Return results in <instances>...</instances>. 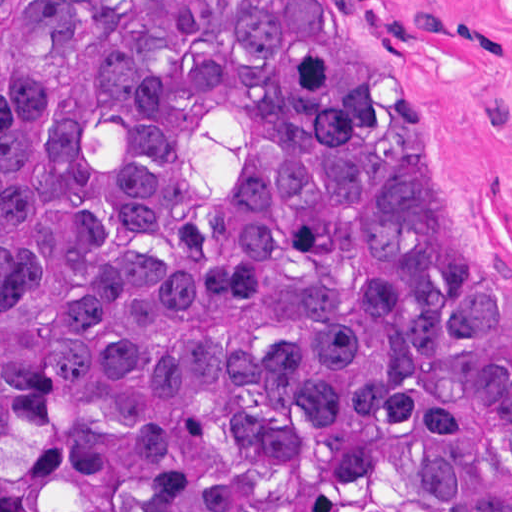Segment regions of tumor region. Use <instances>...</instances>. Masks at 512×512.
<instances>
[{
    "label": "tumor region",
    "instance_id": "1",
    "mask_svg": "<svg viewBox=\"0 0 512 512\" xmlns=\"http://www.w3.org/2000/svg\"><path fill=\"white\" fill-rule=\"evenodd\" d=\"M0 462L26 512H512V349L334 0H0Z\"/></svg>",
    "mask_w": 512,
    "mask_h": 512
}]
</instances>
